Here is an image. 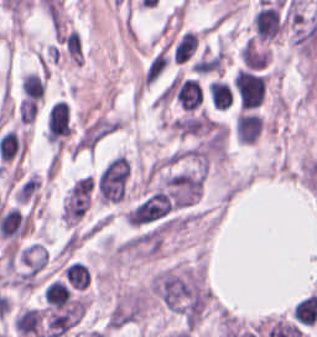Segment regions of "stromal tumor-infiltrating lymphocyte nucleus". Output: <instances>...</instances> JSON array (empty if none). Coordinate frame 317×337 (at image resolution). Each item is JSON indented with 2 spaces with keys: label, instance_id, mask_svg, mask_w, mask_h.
<instances>
[{
  "label": "stromal tumor-infiltrating lymphocyte nucleus",
  "instance_id": "bc302bb0",
  "mask_svg": "<svg viewBox=\"0 0 317 337\" xmlns=\"http://www.w3.org/2000/svg\"><path fill=\"white\" fill-rule=\"evenodd\" d=\"M44 298L50 307L63 308L71 302L72 292L65 282L55 278L44 288Z\"/></svg>",
  "mask_w": 317,
  "mask_h": 337
},
{
  "label": "stromal tumor-infiltrating lymphocyte nucleus",
  "instance_id": "52c7bb5b",
  "mask_svg": "<svg viewBox=\"0 0 317 337\" xmlns=\"http://www.w3.org/2000/svg\"><path fill=\"white\" fill-rule=\"evenodd\" d=\"M198 48V35L193 30H186L173 49V60L187 62Z\"/></svg>",
  "mask_w": 317,
  "mask_h": 337
},
{
  "label": "stromal tumor-infiltrating lymphocyte nucleus",
  "instance_id": "3290ff9b",
  "mask_svg": "<svg viewBox=\"0 0 317 337\" xmlns=\"http://www.w3.org/2000/svg\"><path fill=\"white\" fill-rule=\"evenodd\" d=\"M209 94L215 108H229L234 99L230 82L221 79L210 81Z\"/></svg>",
  "mask_w": 317,
  "mask_h": 337
},
{
  "label": "stromal tumor-infiltrating lymphocyte nucleus",
  "instance_id": "abfb95fc",
  "mask_svg": "<svg viewBox=\"0 0 317 337\" xmlns=\"http://www.w3.org/2000/svg\"><path fill=\"white\" fill-rule=\"evenodd\" d=\"M22 90L28 100H41L45 95L43 76L35 71H28L23 76Z\"/></svg>",
  "mask_w": 317,
  "mask_h": 337
}]
</instances>
